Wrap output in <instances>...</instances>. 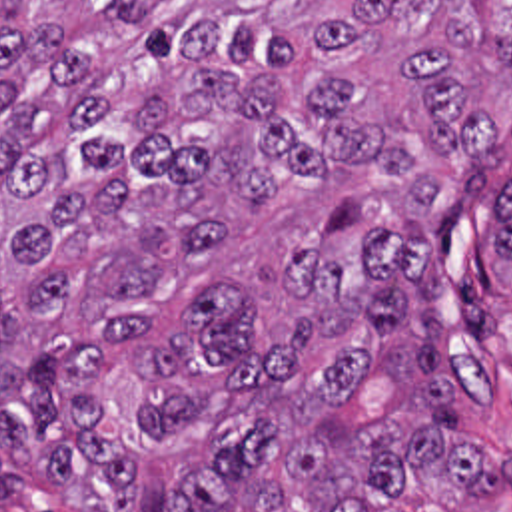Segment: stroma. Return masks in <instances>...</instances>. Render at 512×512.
Returning a JSON list of instances; mask_svg holds the SVG:
<instances>
[{"label":"stroma","mask_w":512,"mask_h":512,"mask_svg":"<svg viewBox=\"0 0 512 512\" xmlns=\"http://www.w3.org/2000/svg\"><path fill=\"white\" fill-rule=\"evenodd\" d=\"M512 185V157L491 169L479 201L457 231L447 275L451 372L485 400L459 396L461 436L512 460V273L495 257L497 219ZM401 512H512V488L501 494L461 490L441 476L417 474L399 494ZM0 512H90L50 482H28L0 496Z\"/></svg>","instance_id":"1"}]
</instances>
